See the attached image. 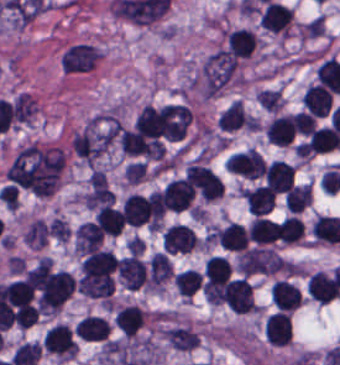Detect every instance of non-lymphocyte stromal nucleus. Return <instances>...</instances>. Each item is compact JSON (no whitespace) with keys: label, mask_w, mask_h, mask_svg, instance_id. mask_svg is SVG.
Here are the masks:
<instances>
[{"label":"non-lymphocyte stromal nucleus","mask_w":340,"mask_h":365,"mask_svg":"<svg viewBox=\"0 0 340 365\" xmlns=\"http://www.w3.org/2000/svg\"><path fill=\"white\" fill-rule=\"evenodd\" d=\"M240 274L257 276L272 274L285 265L282 258L266 248L252 247L239 251L234 263Z\"/></svg>","instance_id":"dd21d789"}]
</instances>
